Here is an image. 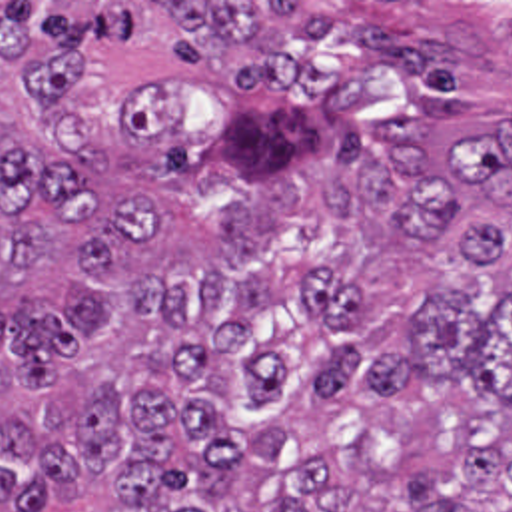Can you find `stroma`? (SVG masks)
<instances>
[{"instance_id":"stroma-1","label":"stroma","mask_w":512,"mask_h":512,"mask_svg":"<svg viewBox=\"0 0 512 512\" xmlns=\"http://www.w3.org/2000/svg\"><path fill=\"white\" fill-rule=\"evenodd\" d=\"M0 2H511L512 0H0Z\"/></svg>"}]
</instances>
